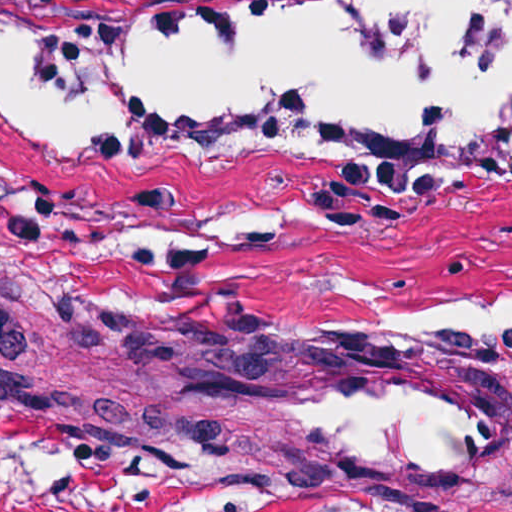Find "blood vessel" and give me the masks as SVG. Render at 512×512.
I'll list each match as a JSON object with an SVG mask.
<instances>
[{"mask_svg": "<svg viewBox=\"0 0 512 512\" xmlns=\"http://www.w3.org/2000/svg\"><path fill=\"white\" fill-rule=\"evenodd\" d=\"M192 380L215 397L312 427L338 469L368 479L453 469L495 448V405L488 398L404 360L195 365Z\"/></svg>", "mask_w": 512, "mask_h": 512, "instance_id": "8fb6f2fc", "label": "blood vessel"}]
</instances>
